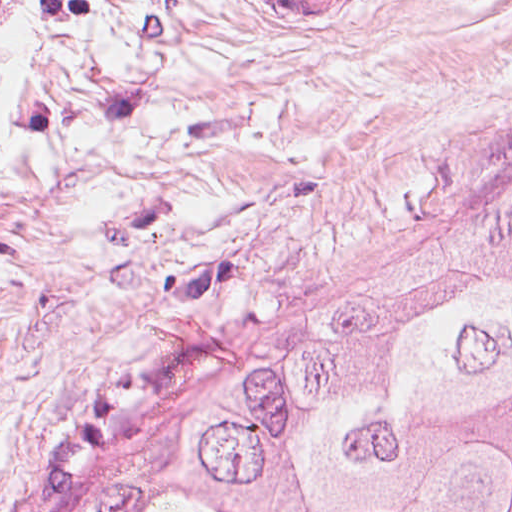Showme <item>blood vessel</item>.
<instances>
[{
    "label": "blood vessel",
    "mask_w": 512,
    "mask_h": 512,
    "mask_svg": "<svg viewBox=\"0 0 512 512\" xmlns=\"http://www.w3.org/2000/svg\"><path fill=\"white\" fill-rule=\"evenodd\" d=\"M280 13L300 21H320L356 0H264Z\"/></svg>",
    "instance_id": "blood-vessel-1"
}]
</instances>
